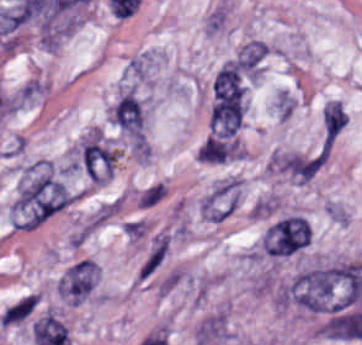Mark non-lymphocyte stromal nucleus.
<instances>
[{"label":"non-lymphocyte stromal nucleus","instance_id":"obj_7","mask_svg":"<svg viewBox=\"0 0 362 345\" xmlns=\"http://www.w3.org/2000/svg\"><path fill=\"white\" fill-rule=\"evenodd\" d=\"M167 193L165 182L158 179L140 190L135 204L139 209H152L162 202Z\"/></svg>","mask_w":362,"mask_h":345},{"label":"non-lymphocyte stromal nucleus","instance_id":"obj_5","mask_svg":"<svg viewBox=\"0 0 362 345\" xmlns=\"http://www.w3.org/2000/svg\"><path fill=\"white\" fill-rule=\"evenodd\" d=\"M111 120L132 137H141L140 108L130 91L115 104Z\"/></svg>","mask_w":362,"mask_h":345},{"label":"non-lymphocyte stromal nucleus","instance_id":"obj_1","mask_svg":"<svg viewBox=\"0 0 362 345\" xmlns=\"http://www.w3.org/2000/svg\"><path fill=\"white\" fill-rule=\"evenodd\" d=\"M73 162L89 180L101 184L115 170L117 149L98 130H91L79 142Z\"/></svg>","mask_w":362,"mask_h":345},{"label":"non-lymphocyte stromal nucleus","instance_id":"obj_6","mask_svg":"<svg viewBox=\"0 0 362 345\" xmlns=\"http://www.w3.org/2000/svg\"><path fill=\"white\" fill-rule=\"evenodd\" d=\"M267 48V44L258 40H251L240 49L236 58L251 77H258L266 57Z\"/></svg>","mask_w":362,"mask_h":345},{"label":"non-lymphocyte stromal nucleus","instance_id":"obj_2","mask_svg":"<svg viewBox=\"0 0 362 345\" xmlns=\"http://www.w3.org/2000/svg\"><path fill=\"white\" fill-rule=\"evenodd\" d=\"M243 193V180L227 174L216 181L198 202L200 216L213 224L230 219L236 211Z\"/></svg>","mask_w":362,"mask_h":345},{"label":"non-lymphocyte stromal nucleus","instance_id":"obj_3","mask_svg":"<svg viewBox=\"0 0 362 345\" xmlns=\"http://www.w3.org/2000/svg\"><path fill=\"white\" fill-rule=\"evenodd\" d=\"M311 231L306 221L290 215L273 223L262 236V251L268 256L286 257L310 245Z\"/></svg>","mask_w":362,"mask_h":345},{"label":"non-lymphocyte stromal nucleus","instance_id":"obj_4","mask_svg":"<svg viewBox=\"0 0 362 345\" xmlns=\"http://www.w3.org/2000/svg\"><path fill=\"white\" fill-rule=\"evenodd\" d=\"M211 90L213 99H245L246 78L238 60L234 58L226 62L215 72Z\"/></svg>","mask_w":362,"mask_h":345}]
</instances>
